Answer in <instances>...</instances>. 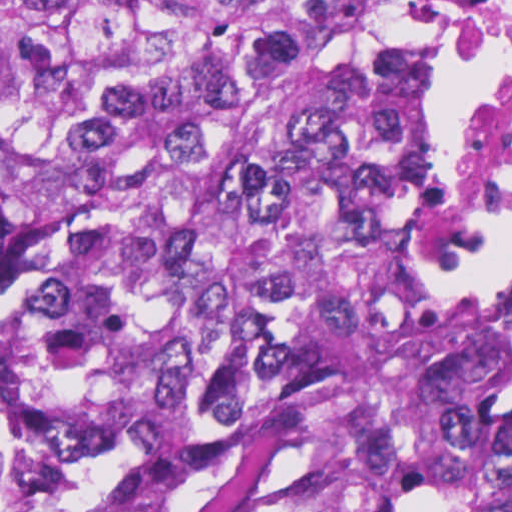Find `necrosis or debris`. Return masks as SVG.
<instances>
[{"label": "necrosis or debris", "instance_id": "necrosis-or-debris-1", "mask_svg": "<svg viewBox=\"0 0 512 512\" xmlns=\"http://www.w3.org/2000/svg\"><path fill=\"white\" fill-rule=\"evenodd\" d=\"M512 207V0H497L460 210V233Z\"/></svg>", "mask_w": 512, "mask_h": 512}]
</instances>
